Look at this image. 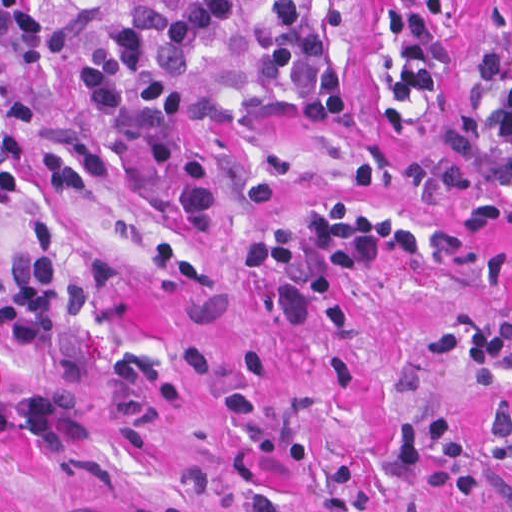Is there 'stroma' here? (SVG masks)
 <instances>
[{"mask_svg": "<svg viewBox=\"0 0 512 512\" xmlns=\"http://www.w3.org/2000/svg\"><path fill=\"white\" fill-rule=\"evenodd\" d=\"M132 0L33 6L63 31L61 55L14 84L1 53L0 512H512V477L485 434L512 404V356L496 370L425 355L432 336L512 319V223L463 244L472 206L438 209L361 186L365 164L457 158L465 77L488 45L490 0H468L437 101L391 141L369 115L371 0H350V107L328 139L275 133L217 183L163 196L203 106L244 71L238 50L204 45L197 84L151 149L117 168L38 172L46 114L87 71L90 39ZM334 195L398 215L425 249L374 259L341 285L349 328L329 331L318 299L282 263L258 269L271 236L300 240ZM55 243L63 329L58 386L79 401V435L26 429L30 362L1 346V290L24 262L33 222ZM442 412L475 461V500L437 499L426 467L395 459L399 420Z\"/></svg>", "mask_w": 512, "mask_h": 512, "instance_id": "1", "label": "stroma"}]
</instances>
